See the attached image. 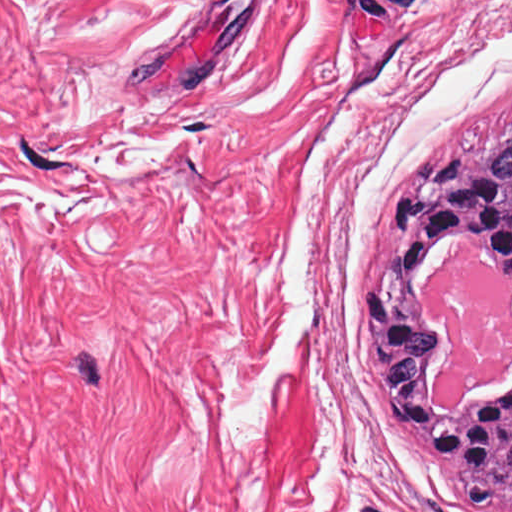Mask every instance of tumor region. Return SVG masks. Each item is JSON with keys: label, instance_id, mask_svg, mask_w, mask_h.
Returning a JSON list of instances; mask_svg holds the SVG:
<instances>
[{"label": "tumor region", "instance_id": "tumor-region-1", "mask_svg": "<svg viewBox=\"0 0 512 512\" xmlns=\"http://www.w3.org/2000/svg\"><path fill=\"white\" fill-rule=\"evenodd\" d=\"M384 218L389 253L353 304L376 336L370 366L378 397L404 431L424 434L474 512H512V373L479 387L460 408H434L430 389L450 342L419 302L422 284L464 241L474 242L481 265L512 286V128L412 166L410 188ZM367 290L387 297V380L423 421L397 416L376 382L377 333L361 313ZM432 430L443 456L428 445Z\"/></svg>", "mask_w": 512, "mask_h": 512}]
</instances>
